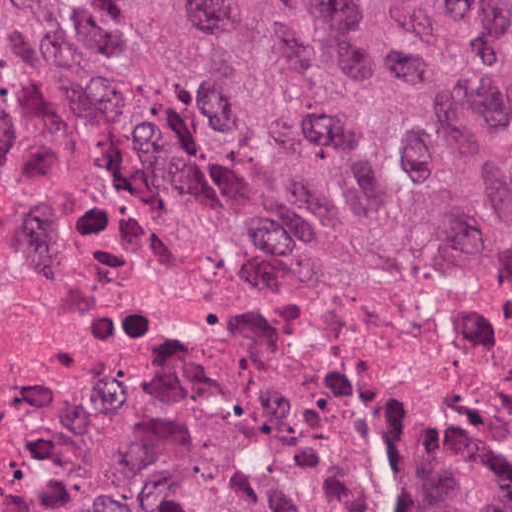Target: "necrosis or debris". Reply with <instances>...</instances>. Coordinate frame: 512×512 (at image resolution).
<instances>
[{"label": "necrosis or debris", "mask_w": 512, "mask_h": 512, "mask_svg": "<svg viewBox=\"0 0 512 512\" xmlns=\"http://www.w3.org/2000/svg\"><path fill=\"white\" fill-rule=\"evenodd\" d=\"M208 436L349 512L435 480L512 512V266H440L82 158L0 40V508L105 451Z\"/></svg>", "instance_id": "1"}]
</instances>
